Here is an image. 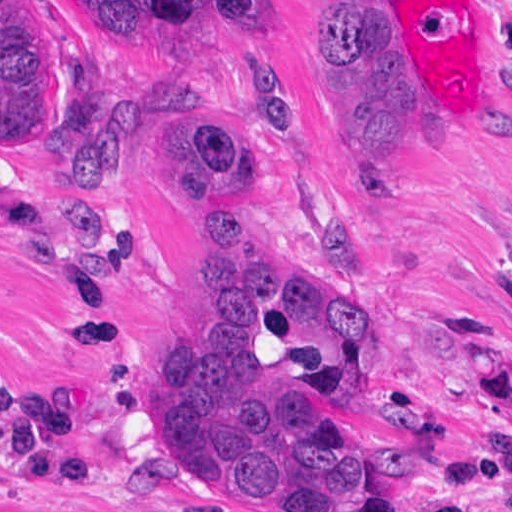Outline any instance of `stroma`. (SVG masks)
Wrapping results in <instances>:
<instances>
[{"instance_id": "1", "label": "stroma", "mask_w": 512, "mask_h": 512, "mask_svg": "<svg viewBox=\"0 0 512 512\" xmlns=\"http://www.w3.org/2000/svg\"><path fill=\"white\" fill-rule=\"evenodd\" d=\"M326 1L265 0L257 33L156 55L85 30L72 0H42L52 33L95 60L134 119L135 153L102 188L53 175L33 146L0 155V377L70 391L115 488H55L0 462V512H264L158 476L149 377L224 305L198 203L161 177L170 82L226 99L277 268L317 288L323 328L350 313L365 330L368 374L332 408L373 468L366 512H512V0H380L381 78L416 119L378 173L325 97ZM253 81L267 101L294 100L296 134L270 132ZM42 182L73 211L128 221L125 250L71 230Z\"/></svg>"}]
</instances>
